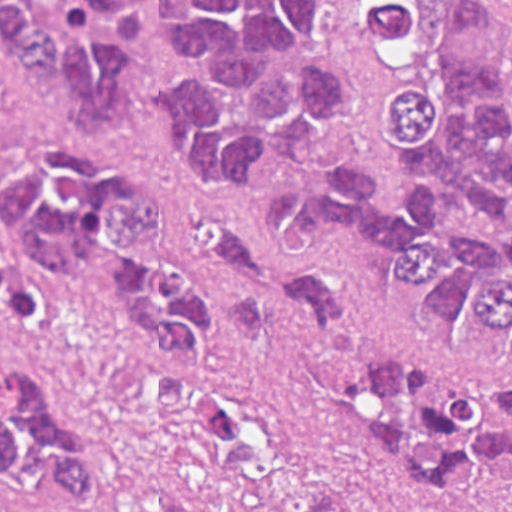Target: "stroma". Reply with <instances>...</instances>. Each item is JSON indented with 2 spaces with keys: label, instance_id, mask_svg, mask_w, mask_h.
Here are the masks:
<instances>
[{
  "label": "stroma",
  "instance_id": "stroma-1",
  "mask_svg": "<svg viewBox=\"0 0 512 512\" xmlns=\"http://www.w3.org/2000/svg\"><path fill=\"white\" fill-rule=\"evenodd\" d=\"M512 94V0H501ZM323 69L340 78L343 111L333 126L336 162L372 165L375 201L407 210L399 163L386 144L384 110L394 95L389 65L366 31L355 0H323L317 31ZM139 82L136 121L123 133L90 131L77 118L69 84L19 69L0 30V158L35 136L72 139L147 177L174 214V263L210 296L226 323L224 342L191 369L124 337L108 320L58 300L32 327L0 323V353L35 364L64 419L97 457L106 512H220L204 458L173 428L168 403L184 388L230 395L266 417L321 477L358 510L380 504L336 431L300 378L240 338L226 319L204 267L208 223H232L272 243L324 291L351 298L366 322L462 368L512 372V364H475L445 347L426 315L390 305L400 255L375 233L333 244H295L267 231L271 197L304 191L319 178L292 163L258 176L249 192H216L184 174L172 157L155 94L180 69L162 43L133 52Z\"/></svg>",
  "mask_w": 512,
  "mask_h": 512
}]
</instances>
